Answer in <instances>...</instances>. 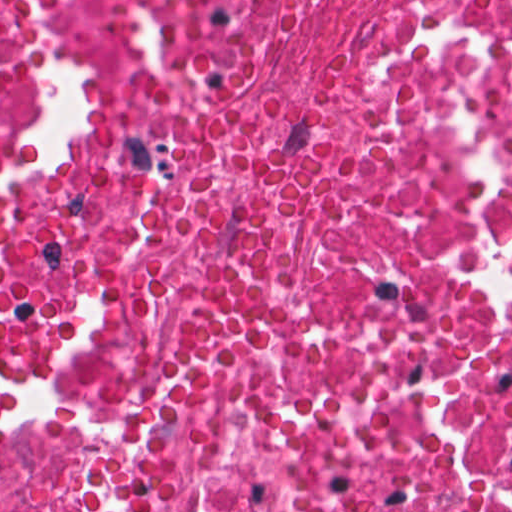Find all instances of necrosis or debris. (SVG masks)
<instances>
[{
    "label": "necrosis or debris",
    "instance_id": "1",
    "mask_svg": "<svg viewBox=\"0 0 512 512\" xmlns=\"http://www.w3.org/2000/svg\"><path fill=\"white\" fill-rule=\"evenodd\" d=\"M0 512H512V0H0Z\"/></svg>",
    "mask_w": 512,
    "mask_h": 512
}]
</instances>
